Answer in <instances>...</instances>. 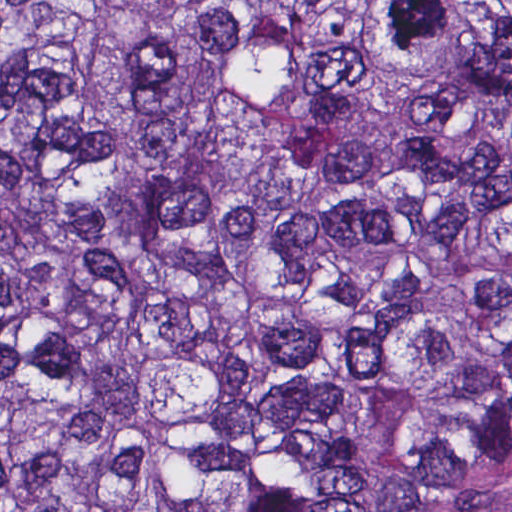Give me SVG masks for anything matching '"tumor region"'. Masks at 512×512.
<instances>
[{"label":"tumor region","mask_w":512,"mask_h":512,"mask_svg":"<svg viewBox=\"0 0 512 512\" xmlns=\"http://www.w3.org/2000/svg\"><path fill=\"white\" fill-rule=\"evenodd\" d=\"M0 512H512V1H0Z\"/></svg>","instance_id":"tumor-region-1"}]
</instances>
